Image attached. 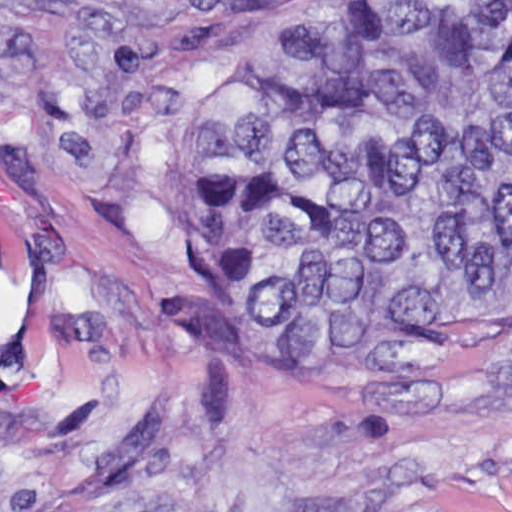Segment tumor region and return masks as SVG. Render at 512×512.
Returning a JSON list of instances; mask_svg holds the SVG:
<instances>
[{
    "instance_id": "e687c5a6",
    "label": "tumor region",
    "mask_w": 512,
    "mask_h": 512,
    "mask_svg": "<svg viewBox=\"0 0 512 512\" xmlns=\"http://www.w3.org/2000/svg\"><path fill=\"white\" fill-rule=\"evenodd\" d=\"M286 50L176 139L165 232L512 295V0H302ZM62 512H197L114 484Z\"/></svg>"
}]
</instances>
